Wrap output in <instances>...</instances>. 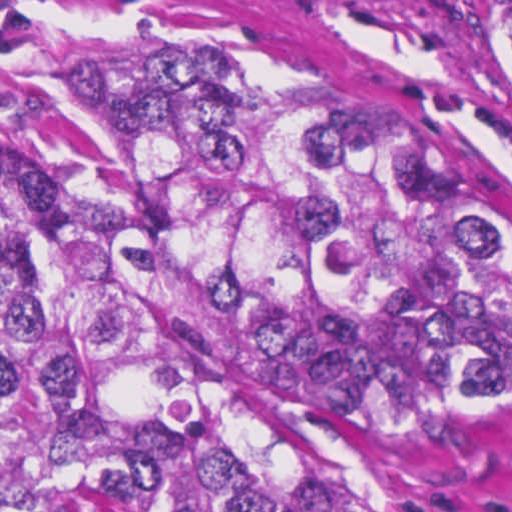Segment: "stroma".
Returning a JSON list of instances; mask_svg holds the SVG:
<instances>
[{"label": "stroma", "mask_w": 512, "mask_h": 512, "mask_svg": "<svg viewBox=\"0 0 512 512\" xmlns=\"http://www.w3.org/2000/svg\"><path fill=\"white\" fill-rule=\"evenodd\" d=\"M471 51L512 73V0H463ZM168 46H292L378 92L512 249V123L470 51L354 0H0V192L102 189L94 144L43 101L132 86ZM270 371L334 451L350 512H512V395L478 421L398 424Z\"/></svg>", "instance_id": "stroma-1"}]
</instances>
